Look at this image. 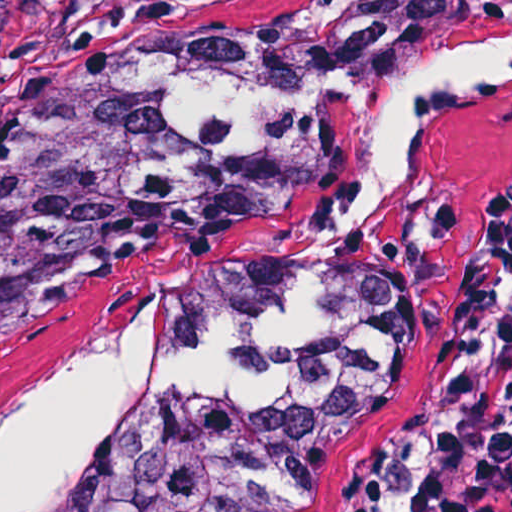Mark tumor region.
<instances>
[{
    "instance_id": "tumor-region-1",
    "label": "tumor region",
    "mask_w": 512,
    "mask_h": 512,
    "mask_svg": "<svg viewBox=\"0 0 512 512\" xmlns=\"http://www.w3.org/2000/svg\"><path fill=\"white\" fill-rule=\"evenodd\" d=\"M439 57H512V0L176 32L0 113V318L155 231L270 223L322 186L373 94ZM405 378L385 271L257 259L163 320L151 413L103 512H336Z\"/></svg>"
}]
</instances>
